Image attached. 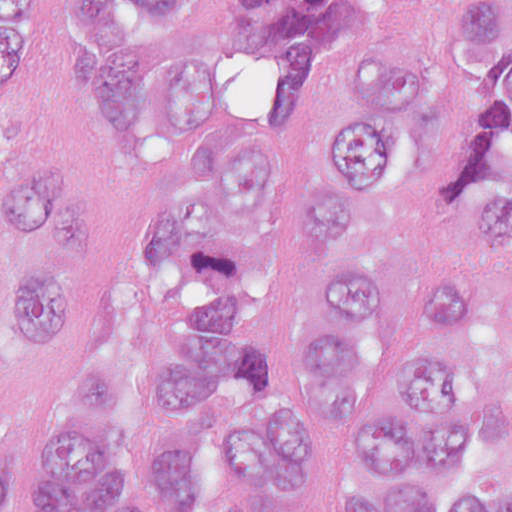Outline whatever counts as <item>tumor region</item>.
I'll return each instance as SVG.
<instances>
[{"mask_svg": "<svg viewBox=\"0 0 512 512\" xmlns=\"http://www.w3.org/2000/svg\"><path fill=\"white\" fill-rule=\"evenodd\" d=\"M90 64L80 134L169 186L50 395L32 512H512V312L463 250L512 248V0H400L436 39L352 43L310 122L253 137L201 0H52ZM369 0H247L254 80L307 87ZM0 0V338L33 352L89 284V177ZM16 451L0 445V512Z\"/></svg>", "mask_w": 512, "mask_h": 512, "instance_id": "e687c5a6", "label": "tumor region"}]
</instances>
